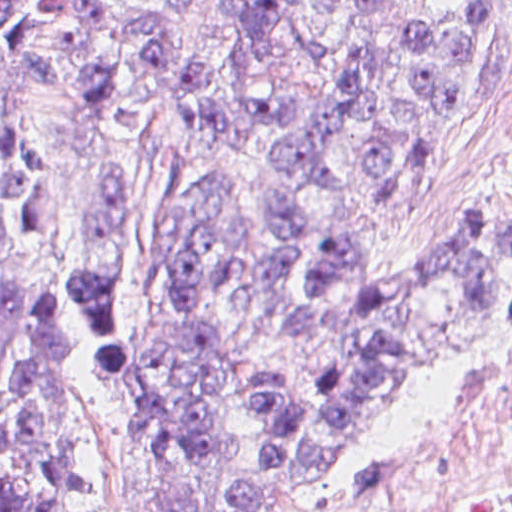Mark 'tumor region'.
Returning a JSON list of instances; mask_svg holds the SVG:
<instances>
[{
    "label": "tumor region",
    "instance_id": "e687c5a6",
    "mask_svg": "<svg viewBox=\"0 0 512 512\" xmlns=\"http://www.w3.org/2000/svg\"><path fill=\"white\" fill-rule=\"evenodd\" d=\"M194 0H0V68L35 83L33 98L59 100L95 137L153 130L152 95L175 54V22ZM384 0H322L355 27L352 64L334 70L327 45L307 39L298 18L307 0H228L251 66L285 48L326 77L321 99L263 98L246 119L287 183L271 189L270 227L295 245L318 215L315 191L341 190L348 173L333 151L363 126L356 162L380 183L394 167L389 116L409 126L402 177L373 203L415 189L421 146L486 59L493 32L479 0L454 16L421 23L404 42L402 89L389 95L374 68ZM214 63L181 65L173 83L176 130L161 145L166 201L159 226V277L170 322L204 300L232 294L293 341L309 390L287 375L256 379L265 456L254 483L212 507L190 501V485L221 451L222 354L215 336L158 345L122 341L108 296L122 167L104 164L88 190L80 273L42 301L0 304V512H100L83 440V343L62 307L82 316L109 352L116 402L134 466L160 512H307L352 488L369 470L380 431L414 388L423 366L485 338L496 250L469 223L389 275L366 280L355 233L314 255L304 280L316 296L288 304L293 266L257 251L232 177L194 173L195 152L226 133L213 93ZM32 101V102H33ZM29 109V105H28ZM50 164L20 133L0 130V252L5 264L46 226ZM487 226L512 259V209Z\"/></svg>",
    "mask_w": 512,
    "mask_h": 512
}]
</instances>
